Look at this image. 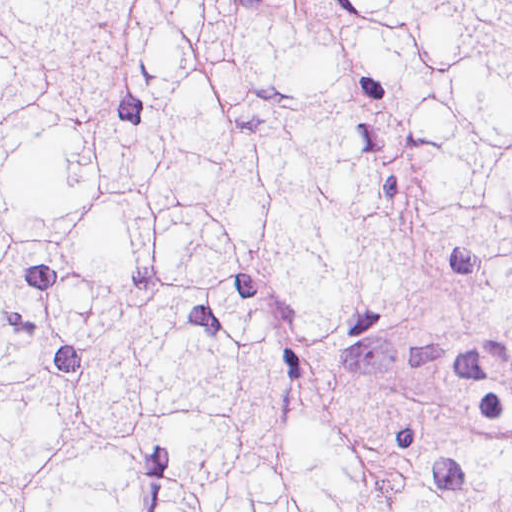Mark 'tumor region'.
<instances>
[{"label": "tumor region", "instance_id": "1", "mask_svg": "<svg viewBox=\"0 0 512 512\" xmlns=\"http://www.w3.org/2000/svg\"><path fill=\"white\" fill-rule=\"evenodd\" d=\"M1 512H512V1H1Z\"/></svg>", "mask_w": 512, "mask_h": 512}]
</instances>
